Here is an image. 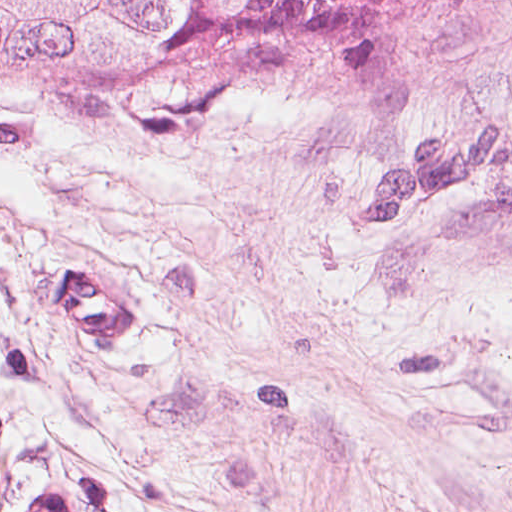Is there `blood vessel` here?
<instances>
[{"label": "blood vessel", "instance_id": "1", "mask_svg": "<svg viewBox=\"0 0 512 512\" xmlns=\"http://www.w3.org/2000/svg\"><path fill=\"white\" fill-rule=\"evenodd\" d=\"M49 317L72 353L109 355L145 326V298L101 279L100 272H62L49 281ZM20 512L66 511L57 491H37Z\"/></svg>", "mask_w": 512, "mask_h": 512}]
</instances>
